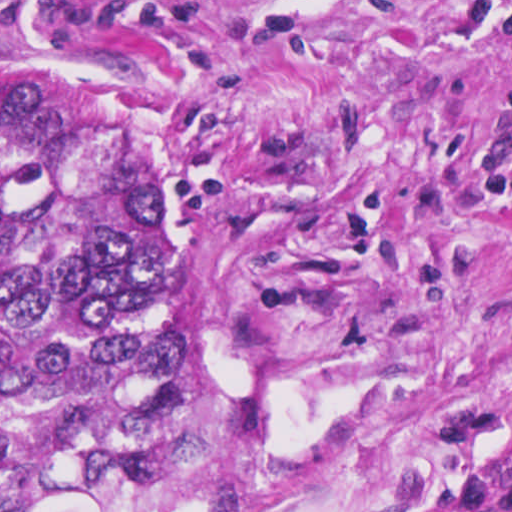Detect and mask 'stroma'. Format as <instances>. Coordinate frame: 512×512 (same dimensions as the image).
I'll return each instance as SVG.
<instances>
[{"mask_svg":"<svg viewBox=\"0 0 512 512\" xmlns=\"http://www.w3.org/2000/svg\"><path fill=\"white\" fill-rule=\"evenodd\" d=\"M0 91L176 221L163 453L46 512H512V0H0Z\"/></svg>","mask_w":512,"mask_h":512,"instance_id":"stroma-1","label":"stroma"}]
</instances>
